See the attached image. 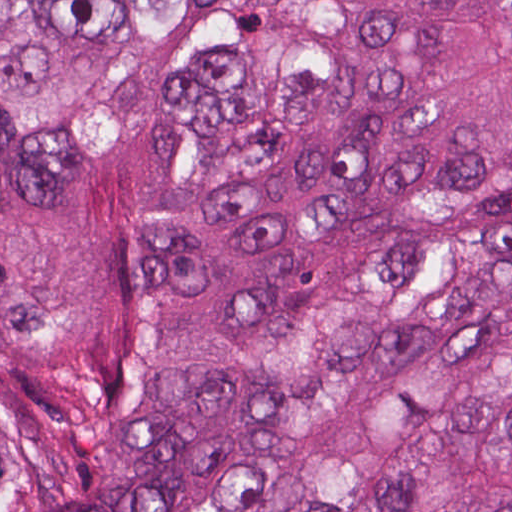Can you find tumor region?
Segmentation results:
<instances>
[{"mask_svg": "<svg viewBox=\"0 0 512 512\" xmlns=\"http://www.w3.org/2000/svg\"><path fill=\"white\" fill-rule=\"evenodd\" d=\"M0 512H512V0H0Z\"/></svg>", "mask_w": 512, "mask_h": 512, "instance_id": "1", "label": "tumor region"}]
</instances>
